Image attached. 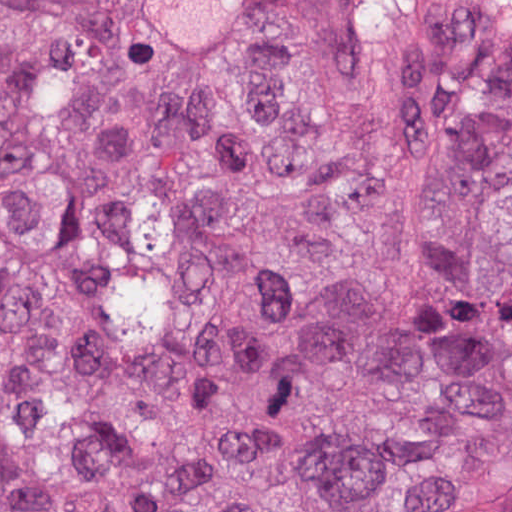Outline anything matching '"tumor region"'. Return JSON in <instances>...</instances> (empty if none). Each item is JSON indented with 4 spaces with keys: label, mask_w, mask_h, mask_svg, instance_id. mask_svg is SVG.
I'll return each mask as SVG.
<instances>
[{
    "label": "tumor region",
    "mask_w": 512,
    "mask_h": 512,
    "mask_svg": "<svg viewBox=\"0 0 512 512\" xmlns=\"http://www.w3.org/2000/svg\"><path fill=\"white\" fill-rule=\"evenodd\" d=\"M0 512H512V8L0 0Z\"/></svg>",
    "instance_id": "obj_1"
}]
</instances>
